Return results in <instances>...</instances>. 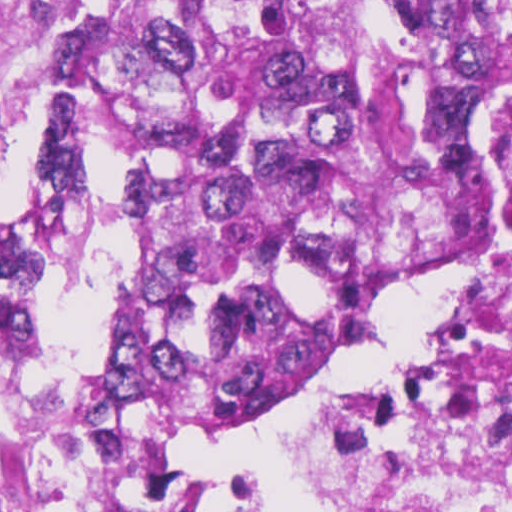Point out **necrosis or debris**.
<instances>
[{"label":"necrosis or debris","mask_w":512,"mask_h":512,"mask_svg":"<svg viewBox=\"0 0 512 512\" xmlns=\"http://www.w3.org/2000/svg\"><path fill=\"white\" fill-rule=\"evenodd\" d=\"M490 85L432 181L386 221L347 299L335 360L390 290L468 253L447 336L377 379L308 449L335 512H512V0L490 9Z\"/></svg>","instance_id":"necrosis-or-debris-1"}]
</instances>
